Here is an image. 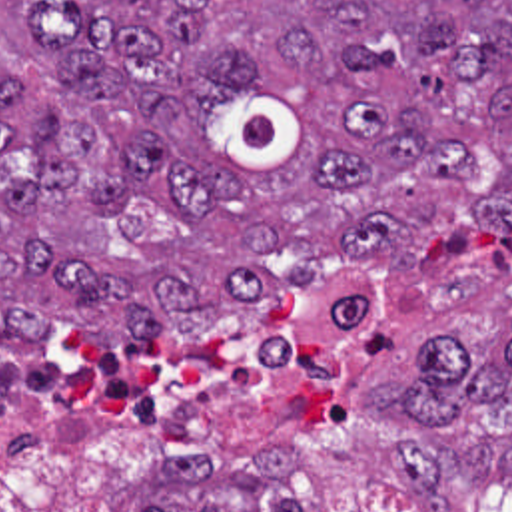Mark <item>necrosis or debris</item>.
Returning <instances> with one entry per match:
<instances>
[{
  "label": "necrosis or debris",
  "instance_id": "obj_1",
  "mask_svg": "<svg viewBox=\"0 0 512 512\" xmlns=\"http://www.w3.org/2000/svg\"><path fill=\"white\" fill-rule=\"evenodd\" d=\"M357 293H277L203 311L141 349L75 327L0 329V476L87 490L147 460H191L283 381L343 357Z\"/></svg>",
  "mask_w": 512,
  "mask_h": 512
}]
</instances>
